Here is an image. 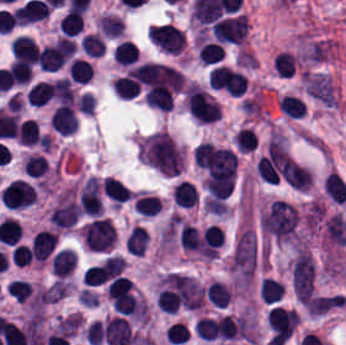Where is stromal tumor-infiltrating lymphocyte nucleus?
<instances>
[{
  "label": "stromal tumor-infiltrating lymphocyte nucleus",
  "instance_id": "8",
  "mask_svg": "<svg viewBox=\"0 0 346 345\" xmlns=\"http://www.w3.org/2000/svg\"><path fill=\"white\" fill-rule=\"evenodd\" d=\"M271 66L280 78H292L299 71V61L294 52L282 50L273 59Z\"/></svg>",
  "mask_w": 346,
  "mask_h": 345
},
{
  "label": "stromal tumor-infiltrating lymphocyte nucleus",
  "instance_id": "27",
  "mask_svg": "<svg viewBox=\"0 0 346 345\" xmlns=\"http://www.w3.org/2000/svg\"><path fill=\"white\" fill-rule=\"evenodd\" d=\"M51 87L55 99L61 103H72L74 91L70 78L57 77L51 82Z\"/></svg>",
  "mask_w": 346,
  "mask_h": 345
},
{
  "label": "stromal tumor-infiltrating lymphocyte nucleus",
  "instance_id": "9",
  "mask_svg": "<svg viewBox=\"0 0 346 345\" xmlns=\"http://www.w3.org/2000/svg\"><path fill=\"white\" fill-rule=\"evenodd\" d=\"M172 199L176 205L183 208H193L199 202L194 184L183 180L174 185Z\"/></svg>",
  "mask_w": 346,
  "mask_h": 345
},
{
  "label": "stromal tumor-infiltrating lymphocyte nucleus",
  "instance_id": "18",
  "mask_svg": "<svg viewBox=\"0 0 346 345\" xmlns=\"http://www.w3.org/2000/svg\"><path fill=\"white\" fill-rule=\"evenodd\" d=\"M25 95L30 105L41 107L52 97L51 86L46 80H39L27 90Z\"/></svg>",
  "mask_w": 346,
  "mask_h": 345
},
{
  "label": "stromal tumor-infiltrating lymphocyte nucleus",
  "instance_id": "10",
  "mask_svg": "<svg viewBox=\"0 0 346 345\" xmlns=\"http://www.w3.org/2000/svg\"><path fill=\"white\" fill-rule=\"evenodd\" d=\"M101 189L118 206L129 200L132 195L130 188L114 177L107 176L101 183Z\"/></svg>",
  "mask_w": 346,
  "mask_h": 345
},
{
  "label": "stromal tumor-infiltrating lymphocyte nucleus",
  "instance_id": "14",
  "mask_svg": "<svg viewBox=\"0 0 346 345\" xmlns=\"http://www.w3.org/2000/svg\"><path fill=\"white\" fill-rule=\"evenodd\" d=\"M225 51L213 41H206L199 44L198 60L203 66H211L224 60Z\"/></svg>",
  "mask_w": 346,
  "mask_h": 345
},
{
  "label": "stromal tumor-infiltrating lymphocyte nucleus",
  "instance_id": "16",
  "mask_svg": "<svg viewBox=\"0 0 346 345\" xmlns=\"http://www.w3.org/2000/svg\"><path fill=\"white\" fill-rule=\"evenodd\" d=\"M134 209L144 218H153L162 209L160 198L153 194H140Z\"/></svg>",
  "mask_w": 346,
  "mask_h": 345
},
{
  "label": "stromal tumor-infiltrating lymphocyte nucleus",
  "instance_id": "28",
  "mask_svg": "<svg viewBox=\"0 0 346 345\" xmlns=\"http://www.w3.org/2000/svg\"><path fill=\"white\" fill-rule=\"evenodd\" d=\"M6 289L8 295L15 303L23 304L29 299L33 291L29 282H26L19 278L12 282H9Z\"/></svg>",
  "mask_w": 346,
  "mask_h": 345
},
{
  "label": "stromal tumor-infiltrating lymphocyte nucleus",
  "instance_id": "20",
  "mask_svg": "<svg viewBox=\"0 0 346 345\" xmlns=\"http://www.w3.org/2000/svg\"><path fill=\"white\" fill-rule=\"evenodd\" d=\"M98 25L103 35L108 37H118L123 35L125 29L123 18L111 13H104L99 20Z\"/></svg>",
  "mask_w": 346,
  "mask_h": 345
},
{
  "label": "stromal tumor-infiltrating lymphocyte nucleus",
  "instance_id": "7",
  "mask_svg": "<svg viewBox=\"0 0 346 345\" xmlns=\"http://www.w3.org/2000/svg\"><path fill=\"white\" fill-rule=\"evenodd\" d=\"M57 234L50 229L38 231L33 236V256L35 262H45L51 255L57 242Z\"/></svg>",
  "mask_w": 346,
  "mask_h": 345
},
{
  "label": "stromal tumor-infiltrating lymphocyte nucleus",
  "instance_id": "33",
  "mask_svg": "<svg viewBox=\"0 0 346 345\" xmlns=\"http://www.w3.org/2000/svg\"><path fill=\"white\" fill-rule=\"evenodd\" d=\"M33 69L26 62L13 61L11 66V77L14 83L25 85L29 82L32 76Z\"/></svg>",
  "mask_w": 346,
  "mask_h": 345
},
{
  "label": "stromal tumor-infiltrating lymphocyte nucleus",
  "instance_id": "3",
  "mask_svg": "<svg viewBox=\"0 0 346 345\" xmlns=\"http://www.w3.org/2000/svg\"><path fill=\"white\" fill-rule=\"evenodd\" d=\"M36 191L33 184L17 179L1 192V202L12 209H21L35 203Z\"/></svg>",
  "mask_w": 346,
  "mask_h": 345
},
{
  "label": "stromal tumor-infiltrating lymphocyte nucleus",
  "instance_id": "22",
  "mask_svg": "<svg viewBox=\"0 0 346 345\" xmlns=\"http://www.w3.org/2000/svg\"><path fill=\"white\" fill-rule=\"evenodd\" d=\"M139 49L129 40H122L116 47L113 57L119 65H132L139 56Z\"/></svg>",
  "mask_w": 346,
  "mask_h": 345
},
{
  "label": "stromal tumor-infiltrating lymphocyte nucleus",
  "instance_id": "1",
  "mask_svg": "<svg viewBox=\"0 0 346 345\" xmlns=\"http://www.w3.org/2000/svg\"><path fill=\"white\" fill-rule=\"evenodd\" d=\"M81 237L88 250L104 252L114 245L116 232L107 219L97 218L82 226Z\"/></svg>",
  "mask_w": 346,
  "mask_h": 345
},
{
  "label": "stromal tumor-infiltrating lymphocyte nucleus",
  "instance_id": "4",
  "mask_svg": "<svg viewBox=\"0 0 346 345\" xmlns=\"http://www.w3.org/2000/svg\"><path fill=\"white\" fill-rule=\"evenodd\" d=\"M50 122L58 133L73 134L78 125V119L72 103L67 102L55 109L51 114Z\"/></svg>",
  "mask_w": 346,
  "mask_h": 345
},
{
  "label": "stromal tumor-infiltrating lymphocyte nucleus",
  "instance_id": "35",
  "mask_svg": "<svg viewBox=\"0 0 346 345\" xmlns=\"http://www.w3.org/2000/svg\"><path fill=\"white\" fill-rule=\"evenodd\" d=\"M77 110L85 113L92 114L95 109V96L89 92H82L76 102Z\"/></svg>",
  "mask_w": 346,
  "mask_h": 345
},
{
  "label": "stromal tumor-infiltrating lymphocyte nucleus",
  "instance_id": "31",
  "mask_svg": "<svg viewBox=\"0 0 346 345\" xmlns=\"http://www.w3.org/2000/svg\"><path fill=\"white\" fill-rule=\"evenodd\" d=\"M25 173L30 177H44L46 174L47 160L41 155L28 154L24 161Z\"/></svg>",
  "mask_w": 346,
  "mask_h": 345
},
{
  "label": "stromal tumor-infiltrating lymphocyte nucleus",
  "instance_id": "12",
  "mask_svg": "<svg viewBox=\"0 0 346 345\" xmlns=\"http://www.w3.org/2000/svg\"><path fill=\"white\" fill-rule=\"evenodd\" d=\"M42 139L40 126L34 118H27L18 125L17 140L19 144L34 146Z\"/></svg>",
  "mask_w": 346,
  "mask_h": 345
},
{
  "label": "stromal tumor-infiltrating lymphocyte nucleus",
  "instance_id": "17",
  "mask_svg": "<svg viewBox=\"0 0 346 345\" xmlns=\"http://www.w3.org/2000/svg\"><path fill=\"white\" fill-rule=\"evenodd\" d=\"M327 193L333 202H346V182L337 172H330L324 180Z\"/></svg>",
  "mask_w": 346,
  "mask_h": 345
},
{
  "label": "stromal tumor-infiltrating lymphocyte nucleus",
  "instance_id": "25",
  "mask_svg": "<svg viewBox=\"0 0 346 345\" xmlns=\"http://www.w3.org/2000/svg\"><path fill=\"white\" fill-rule=\"evenodd\" d=\"M283 298V283L271 277H264L261 288L262 303H276Z\"/></svg>",
  "mask_w": 346,
  "mask_h": 345
},
{
  "label": "stromal tumor-infiltrating lymphocyte nucleus",
  "instance_id": "5",
  "mask_svg": "<svg viewBox=\"0 0 346 345\" xmlns=\"http://www.w3.org/2000/svg\"><path fill=\"white\" fill-rule=\"evenodd\" d=\"M66 62V45L55 43L39 50V65L43 71H56Z\"/></svg>",
  "mask_w": 346,
  "mask_h": 345
},
{
  "label": "stromal tumor-infiltrating lymphocyte nucleus",
  "instance_id": "24",
  "mask_svg": "<svg viewBox=\"0 0 346 345\" xmlns=\"http://www.w3.org/2000/svg\"><path fill=\"white\" fill-rule=\"evenodd\" d=\"M69 75L71 81L87 84L92 79L91 62L82 57H75L71 61Z\"/></svg>",
  "mask_w": 346,
  "mask_h": 345
},
{
  "label": "stromal tumor-infiltrating lymphocyte nucleus",
  "instance_id": "6",
  "mask_svg": "<svg viewBox=\"0 0 346 345\" xmlns=\"http://www.w3.org/2000/svg\"><path fill=\"white\" fill-rule=\"evenodd\" d=\"M13 60L36 64L40 49L29 36L17 35L11 43Z\"/></svg>",
  "mask_w": 346,
  "mask_h": 345
},
{
  "label": "stromal tumor-infiltrating lymphocyte nucleus",
  "instance_id": "2",
  "mask_svg": "<svg viewBox=\"0 0 346 345\" xmlns=\"http://www.w3.org/2000/svg\"><path fill=\"white\" fill-rule=\"evenodd\" d=\"M150 41L166 52H182L186 45L184 30L167 23L150 28Z\"/></svg>",
  "mask_w": 346,
  "mask_h": 345
},
{
  "label": "stromal tumor-infiltrating lymphocyte nucleus",
  "instance_id": "34",
  "mask_svg": "<svg viewBox=\"0 0 346 345\" xmlns=\"http://www.w3.org/2000/svg\"><path fill=\"white\" fill-rule=\"evenodd\" d=\"M15 266H24L33 260V249L24 244H17L11 252Z\"/></svg>",
  "mask_w": 346,
  "mask_h": 345
},
{
  "label": "stromal tumor-infiltrating lymphocyte nucleus",
  "instance_id": "19",
  "mask_svg": "<svg viewBox=\"0 0 346 345\" xmlns=\"http://www.w3.org/2000/svg\"><path fill=\"white\" fill-rule=\"evenodd\" d=\"M80 45L88 57H102L107 48L102 34L99 33H86Z\"/></svg>",
  "mask_w": 346,
  "mask_h": 345
},
{
  "label": "stromal tumor-infiltrating lymphocyte nucleus",
  "instance_id": "32",
  "mask_svg": "<svg viewBox=\"0 0 346 345\" xmlns=\"http://www.w3.org/2000/svg\"><path fill=\"white\" fill-rule=\"evenodd\" d=\"M234 143L238 151L251 152L256 148V134L252 128H242L235 136Z\"/></svg>",
  "mask_w": 346,
  "mask_h": 345
},
{
  "label": "stromal tumor-infiltrating lymphocyte nucleus",
  "instance_id": "26",
  "mask_svg": "<svg viewBox=\"0 0 346 345\" xmlns=\"http://www.w3.org/2000/svg\"><path fill=\"white\" fill-rule=\"evenodd\" d=\"M207 297L213 304L226 308L232 298V292L224 283L215 280L208 287Z\"/></svg>",
  "mask_w": 346,
  "mask_h": 345
},
{
  "label": "stromal tumor-infiltrating lymphocyte nucleus",
  "instance_id": "11",
  "mask_svg": "<svg viewBox=\"0 0 346 345\" xmlns=\"http://www.w3.org/2000/svg\"><path fill=\"white\" fill-rule=\"evenodd\" d=\"M77 263L76 255L70 249L57 251L52 262V272L56 276H70Z\"/></svg>",
  "mask_w": 346,
  "mask_h": 345
},
{
  "label": "stromal tumor-infiltrating lymphocyte nucleus",
  "instance_id": "30",
  "mask_svg": "<svg viewBox=\"0 0 346 345\" xmlns=\"http://www.w3.org/2000/svg\"><path fill=\"white\" fill-rule=\"evenodd\" d=\"M195 331L203 340L213 341L216 340L218 333V324L215 318L202 316L196 323Z\"/></svg>",
  "mask_w": 346,
  "mask_h": 345
},
{
  "label": "stromal tumor-infiltrating lymphocyte nucleus",
  "instance_id": "13",
  "mask_svg": "<svg viewBox=\"0 0 346 345\" xmlns=\"http://www.w3.org/2000/svg\"><path fill=\"white\" fill-rule=\"evenodd\" d=\"M150 236L144 226H135L129 234L125 248L131 255L143 256L146 253Z\"/></svg>",
  "mask_w": 346,
  "mask_h": 345
},
{
  "label": "stromal tumor-infiltrating lymphocyte nucleus",
  "instance_id": "15",
  "mask_svg": "<svg viewBox=\"0 0 346 345\" xmlns=\"http://www.w3.org/2000/svg\"><path fill=\"white\" fill-rule=\"evenodd\" d=\"M113 90L120 99H132L141 92V85L132 76H119L113 84Z\"/></svg>",
  "mask_w": 346,
  "mask_h": 345
},
{
  "label": "stromal tumor-infiltrating lymphocyte nucleus",
  "instance_id": "29",
  "mask_svg": "<svg viewBox=\"0 0 346 345\" xmlns=\"http://www.w3.org/2000/svg\"><path fill=\"white\" fill-rule=\"evenodd\" d=\"M165 339L171 345H183L190 339V331L187 326L177 321L167 326Z\"/></svg>",
  "mask_w": 346,
  "mask_h": 345
},
{
  "label": "stromal tumor-infiltrating lymphocyte nucleus",
  "instance_id": "23",
  "mask_svg": "<svg viewBox=\"0 0 346 345\" xmlns=\"http://www.w3.org/2000/svg\"><path fill=\"white\" fill-rule=\"evenodd\" d=\"M280 109L283 114L293 118H303L305 115V103L302 98L294 94H285L280 97Z\"/></svg>",
  "mask_w": 346,
  "mask_h": 345
},
{
  "label": "stromal tumor-infiltrating lymphocyte nucleus",
  "instance_id": "21",
  "mask_svg": "<svg viewBox=\"0 0 346 345\" xmlns=\"http://www.w3.org/2000/svg\"><path fill=\"white\" fill-rule=\"evenodd\" d=\"M83 13L69 9L59 22V31L65 36H74L81 32Z\"/></svg>",
  "mask_w": 346,
  "mask_h": 345
}]
</instances>
